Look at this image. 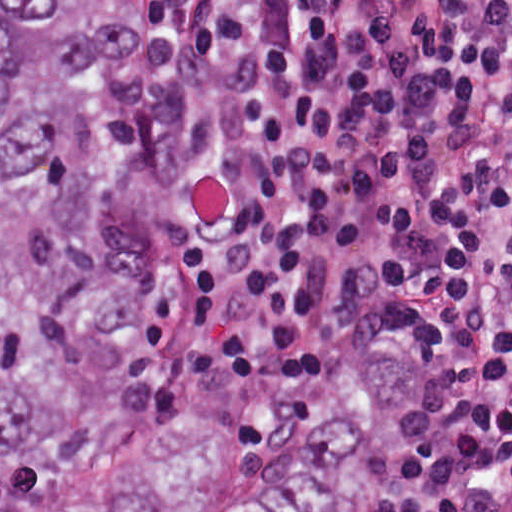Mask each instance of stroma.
I'll return each mask as SVG.
<instances>
[{
	"mask_svg": "<svg viewBox=\"0 0 512 512\" xmlns=\"http://www.w3.org/2000/svg\"><path fill=\"white\" fill-rule=\"evenodd\" d=\"M148 1L163 20L175 51V34L172 16L165 0ZM178 178L171 194L169 221L166 228V301L172 314L173 343L180 373L192 394L205 408L212 423L226 437L241 442H263L286 438L254 434L232 421L217 396L198 377L185 355L180 329L185 306V250L176 236V192ZM424 477L425 440L419 417L412 457L398 495V512H418Z\"/></svg>",
	"mask_w": 512,
	"mask_h": 512,
	"instance_id": "1",
	"label": "stroma"
}]
</instances>
